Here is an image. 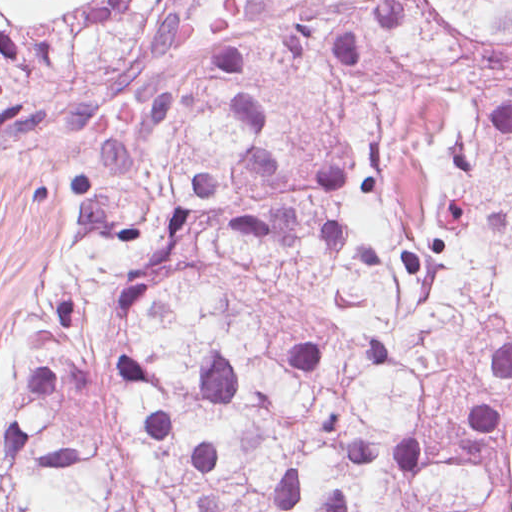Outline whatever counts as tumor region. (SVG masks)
Returning <instances> with one entry per match:
<instances>
[{"mask_svg": "<svg viewBox=\"0 0 512 512\" xmlns=\"http://www.w3.org/2000/svg\"><path fill=\"white\" fill-rule=\"evenodd\" d=\"M78 129L0 512H512V0H0Z\"/></svg>", "mask_w": 512, "mask_h": 512, "instance_id": "e687c5a6", "label": "tumor region"}]
</instances>
